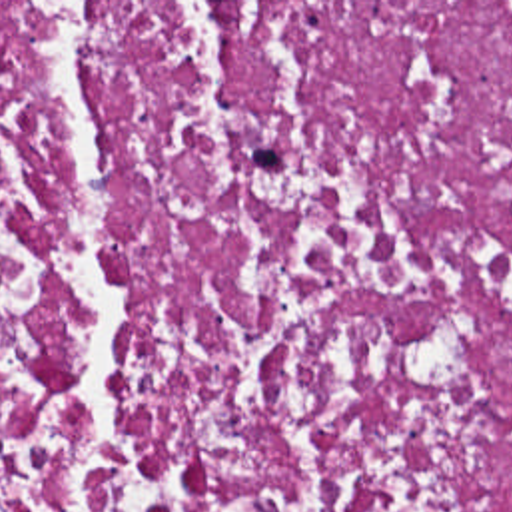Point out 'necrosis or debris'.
<instances>
[{
    "mask_svg": "<svg viewBox=\"0 0 512 512\" xmlns=\"http://www.w3.org/2000/svg\"><path fill=\"white\" fill-rule=\"evenodd\" d=\"M0 512H512V2H0Z\"/></svg>",
    "mask_w": 512,
    "mask_h": 512,
    "instance_id": "1",
    "label": "necrosis or debris"
}]
</instances>
